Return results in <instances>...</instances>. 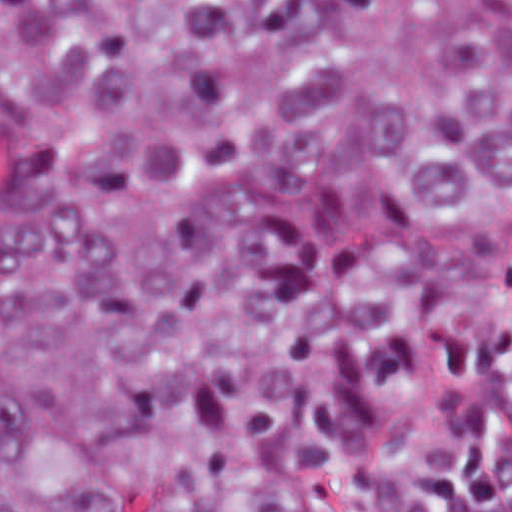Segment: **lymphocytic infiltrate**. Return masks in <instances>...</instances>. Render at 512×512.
I'll return each instance as SVG.
<instances>
[{"instance_id": "f902f5d3", "label": "lymphocytic infiltrate", "mask_w": 512, "mask_h": 512, "mask_svg": "<svg viewBox=\"0 0 512 512\" xmlns=\"http://www.w3.org/2000/svg\"><path fill=\"white\" fill-rule=\"evenodd\" d=\"M512 274L453 345L373 512H512Z\"/></svg>"}]
</instances>
